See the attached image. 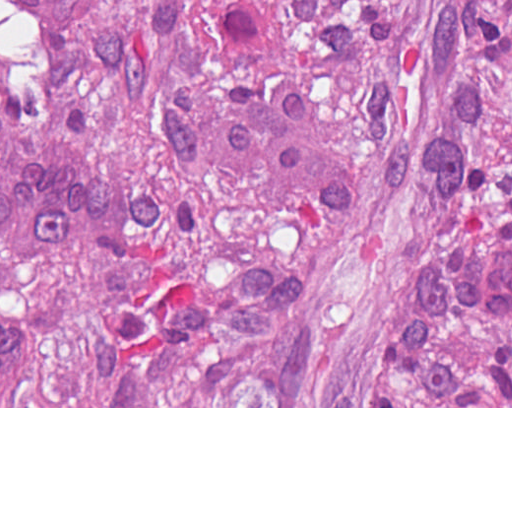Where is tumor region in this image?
Wrapping results in <instances>:
<instances>
[{"mask_svg": "<svg viewBox=\"0 0 512 512\" xmlns=\"http://www.w3.org/2000/svg\"><path fill=\"white\" fill-rule=\"evenodd\" d=\"M98 179L63 258L0 251L12 406H512V0H0V161Z\"/></svg>", "mask_w": 512, "mask_h": 512, "instance_id": "1", "label": "tumor region"}]
</instances>
